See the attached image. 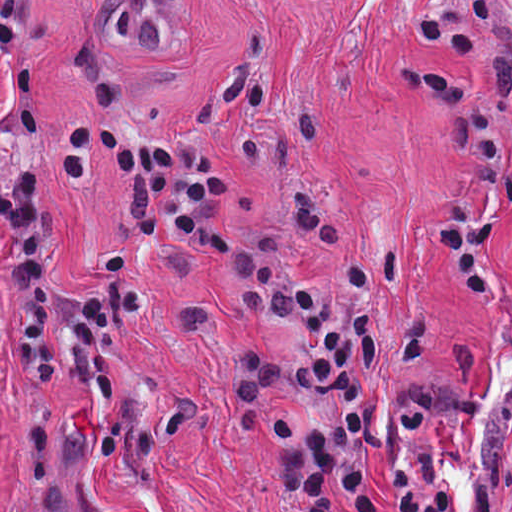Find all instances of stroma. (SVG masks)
<instances>
[{"label":"stroma","instance_id":"1","mask_svg":"<svg viewBox=\"0 0 512 512\" xmlns=\"http://www.w3.org/2000/svg\"><path fill=\"white\" fill-rule=\"evenodd\" d=\"M510 0H501V6ZM466 0H39L35 111L46 146L50 315L40 346L63 338L68 299L105 276L128 193L93 151L82 185L49 173L53 128L92 109L124 122L193 132L230 174L216 258L153 245L131 261L152 298L283 239L292 184L335 180L349 209L443 167V114L408 96L400 55L431 79L453 76L479 96L495 87L482 62L412 24ZM12 88L0 68V183L11 177ZM11 356V280L0 241V365Z\"/></svg>","mask_w":512,"mask_h":512}]
</instances>
